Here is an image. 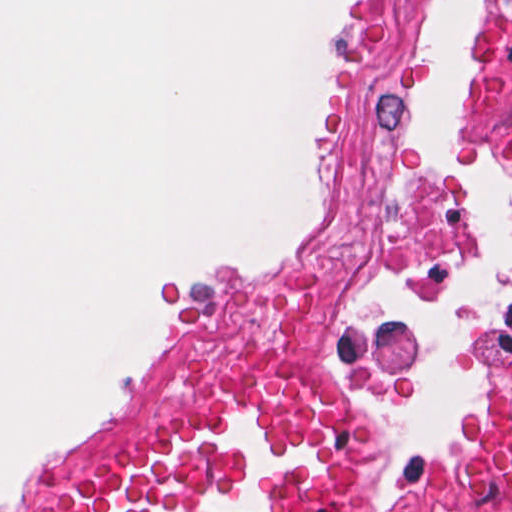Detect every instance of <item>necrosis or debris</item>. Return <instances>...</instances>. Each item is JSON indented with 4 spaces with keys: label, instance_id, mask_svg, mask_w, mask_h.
<instances>
[{
    "label": "necrosis or debris",
    "instance_id": "obj_1",
    "mask_svg": "<svg viewBox=\"0 0 512 512\" xmlns=\"http://www.w3.org/2000/svg\"><path fill=\"white\" fill-rule=\"evenodd\" d=\"M398 3L366 1L345 174L323 248L302 260L208 273L173 297L147 408L169 403L185 368L221 349H313L377 381L394 368L391 340L352 309L341 270L374 256H435L454 242L451 198L424 172L414 145ZM394 512H512V343L490 353L469 454Z\"/></svg>",
    "mask_w": 512,
    "mask_h": 512
}]
</instances>
